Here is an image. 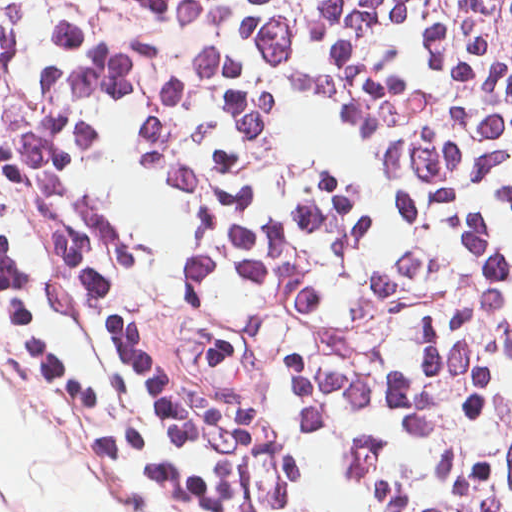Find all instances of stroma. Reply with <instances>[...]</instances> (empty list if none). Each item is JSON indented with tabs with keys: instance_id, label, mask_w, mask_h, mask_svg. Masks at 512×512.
Listing matches in <instances>:
<instances>
[{
	"instance_id": "35a3bbf8",
	"label": "stroma",
	"mask_w": 512,
	"mask_h": 512,
	"mask_svg": "<svg viewBox=\"0 0 512 512\" xmlns=\"http://www.w3.org/2000/svg\"><path fill=\"white\" fill-rule=\"evenodd\" d=\"M0 372L23 388L43 420L60 435L104 504L116 512H148L115 462L96 413L60 359L52 326L8 244L0 207ZM3 512L13 505L0 486Z\"/></svg>"
}]
</instances>
